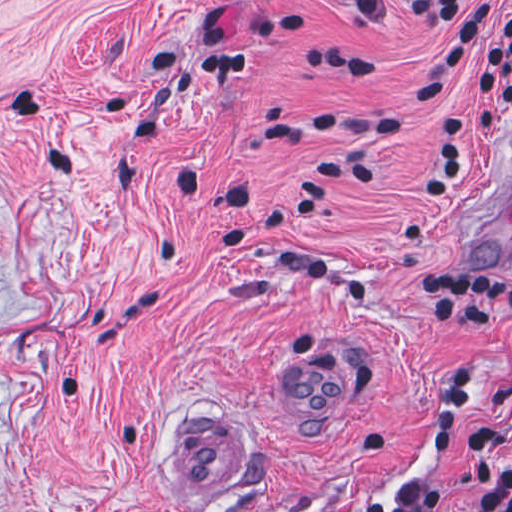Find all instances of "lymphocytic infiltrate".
<instances>
[{"label": "lymphocytic infiltrate", "instance_id": "obj_1", "mask_svg": "<svg viewBox=\"0 0 512 512\" xmlns=\"http://www.w3.org/2000/svg\"><path fill=\"white\" fill-rule=\"evenodd\" d=\"M356 20L372 28L395 26L407 16L433 27L457 23L440 41L428 65L394 110L372 111L342 104H300L284 113L259 116L252 135L274 139L294 133H326L340 140L381 146L396 135L409 116L435 103L453 84L467 49L476 40L475 68L482 85L478 103L448 107L440 119L432 163L422 182L421 200L441 204L460 186L470 140L492 135L494 117L512 114V12L483 0H340ZM201 72L234 76L249 66V54L229 43L220 23L200 29ZM307 67L336 74H374V61L338 51L302 46L298 52ZM375 179V166L365 161L332 156L308 175L295 198L266 206L246 217L254 191L239 184L230 189L216 218L217 243L243 246L274 265L303 278H324L332 270L328 257L308 249L264 243L250 227L289 226L313 212L342 182L365 184ZM413 301L428 331L512 329V277L455 263L425 265L413 279ZM475 384L470 344L459 346L453 363V385L437 411L451 437ZM500 392L512 419V375ZM449 439L438 447L419 450L425 458L441 457ZM473 496L463 512H512V468L501 466L496 444L488 433L469 437ZM357 512H439L437 488L421 478L407 489L400 508L377 493Z\"/></svg>", "mask_w": 512, "mask_h": 512}]
</instances>
